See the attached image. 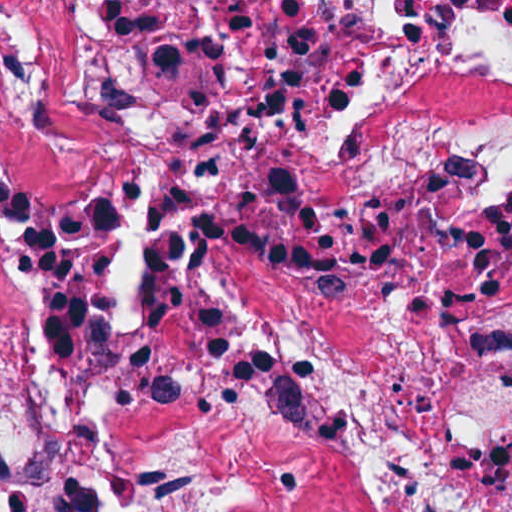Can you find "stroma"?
Segmentation results:
<instances>
[{
  "mask_svg": "<svg viewBox=\"0 0 512 512\" xmlns=\"http://www.w3.org/2000/svg\"><path fill=\"white\" fill-rule=\"evenodd\" d=\"M0 1H512V0H0Z\"/></svg>",
  "mask_w": 512,
  "mask_h": 512,
  "instance_id": "35a3bbf8",
  "label": "stroma"
}]
</instances>
